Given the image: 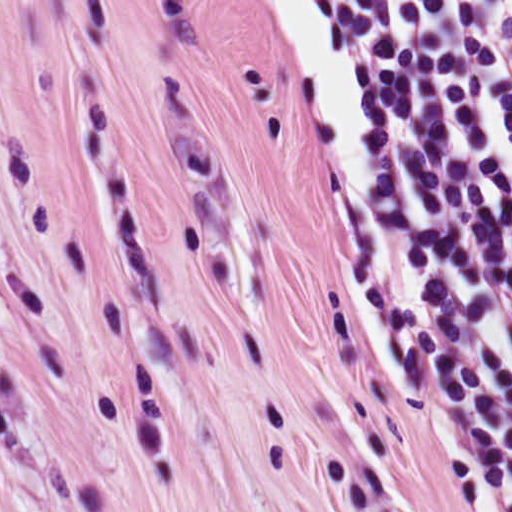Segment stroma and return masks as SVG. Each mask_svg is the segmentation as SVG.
<instances>
[{"instance_id": "stroma-1", "label": "stroma", "mask_w": 512, "mask_h": 512, "mask_svg": "<svg viewBox=\"0 0 512 512\" xmlns=\"http://www.w3.org/2000/svg\"><path fill=\"white\" fill-rule=\"evenodd\" d=\"M0 512H483L279 0H0Z\"/></svg>"}]
</instances>
